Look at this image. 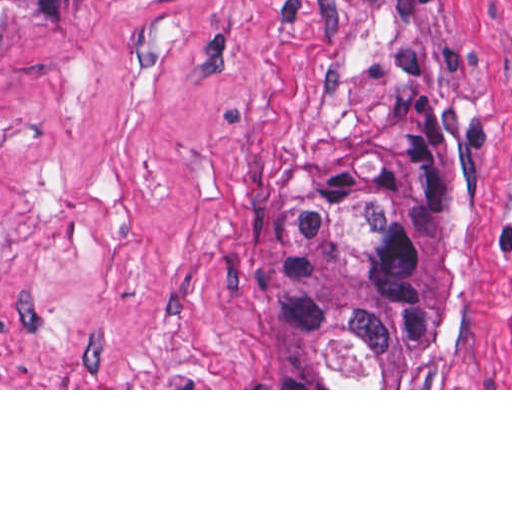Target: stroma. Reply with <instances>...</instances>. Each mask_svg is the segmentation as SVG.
<instances>
[{
    "instance_id": "obj_1",
    "label": "stroma",
    "mask_w": 512,
    "mask_h": 512,
    "mask_svg": "<svg viewBox=\"0 0 512 512\" xmlns=\"http://www.w3.org/2000/svg\"><path fill=\"white\" fill-rule=\"evenodd\" d=\"M459 113L405 388H289L273 225ZM512 0H85L0 47V390H512Z\"/></svg>"
}]
</instances>
